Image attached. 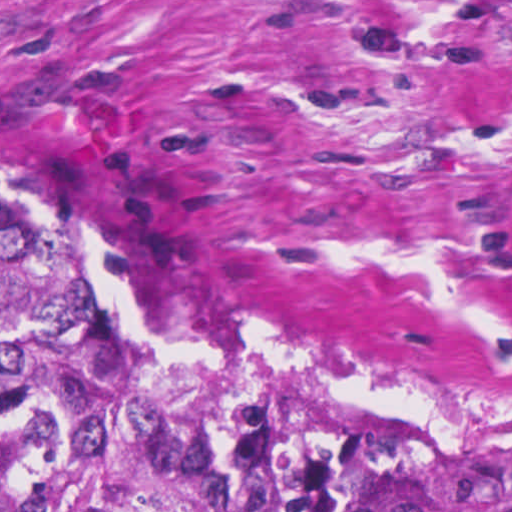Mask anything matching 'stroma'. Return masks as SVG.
Wrapping results in <instances>:
<instances>
[{"instance_id":"35a3bbf8","label":"stroma","mask_w":512,"mask_h":512,"mask_svg":"<svg viewBox=\"0 0 512 512\" xmlns=\"http://www.w3.org/2000/svg\"><path fill=\"white\" fill-rule=\"evenodd\" d=\"M0 166L131 326L512 428V0H0Z\"/></svg>"}]
</instances>
